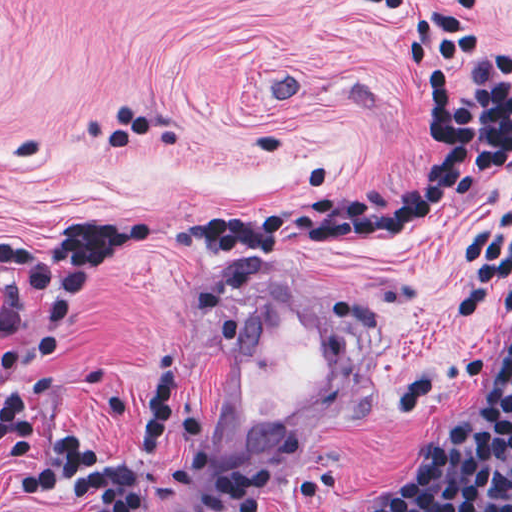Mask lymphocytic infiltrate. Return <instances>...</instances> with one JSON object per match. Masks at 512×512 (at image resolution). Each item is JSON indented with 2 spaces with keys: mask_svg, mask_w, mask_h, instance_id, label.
I'll use <instances>...</instances> for the list:
<instances>
[{
  "mask_svg": "<svg viewBox=\"0 0 512 512\" xmlns=\"http://www.w3.org/2000/svg\"><path fill=\"white\" fill-rule=\"evenodd\" d=\"M479 1H363L361 9L396 28L401 69L422 104V128L435 157L421 181L343 195L325 171L304 173L298 190L257 207L208 215L76 211L65 243L39 246L0 239V339L21 333L32 306L37 334L2 362L0 453L22 501L67 499L84 512H261L269 470L230 464L195 472L208 447L206 426L178 415L177 449L162 457L169 432L176 358L152 355L135 423L117 441L96 443L70 431H39L25 399V364L62 338L87 289L119 253L144 248L219 253L239 260L306 253L402 233L463 193L512 171V51L493 54L468 88L455 73L474 63L480 43L469 17ZM147 131L126 109L108 136L114 154ZM512 308V261L502 276ZM384 512H512V335L469 420L423 439L402 491Z\"/></svg>",
  "mask_w": 512,
  "mask_h": 512,
  "instance_id": "lymphocytic-infiltrate-1",
  "label": "lymphocytic infiltrate"
}]
</instances>
